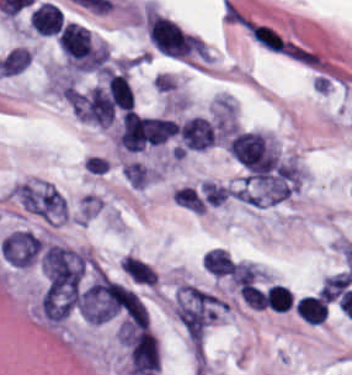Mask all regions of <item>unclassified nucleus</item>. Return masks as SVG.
I'll use <instances>...</instances> for the list:
<instances>
[{"instance_id":"unclassified-nucleus-1","label":"unclassified nucleus","mask_w":352,"mask_h":375,"mask_svg":"<svg viewBox=\"0 0 352 375\" xmlns=\"http://www.w3.org/2000/svg\"><path fill=\"white\" fill-rule=\"evenodd\" d=\"M120 341L130 370L136 375H149L160 365L158 339L152 332L123 321Z\"/></svg>"}]
</instances>
